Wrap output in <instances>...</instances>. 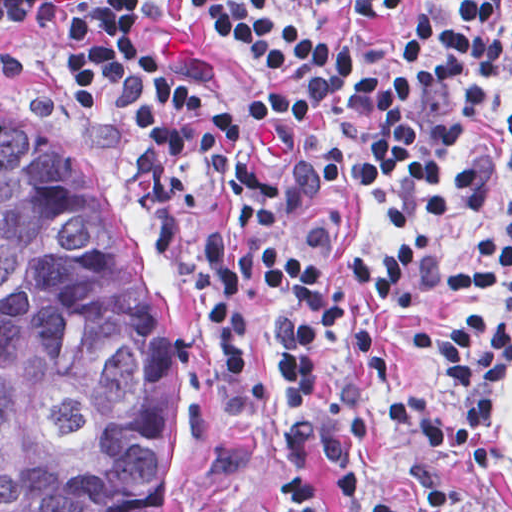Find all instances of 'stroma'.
Instances as JSON below:
<instances>
[{
	"mask_svg": "<svg viewBox=\"0 0 512 512\" xmlns=\"http://www.w3.org/2000/svg\"><path fill=\"white\" fill-rule=\"evenodd\" d=\"M0 1H498L512 23V0H0ZM66 36L56 24L0 21V120L18 128L64 132L84 141L112 211L133 253L169 306V487L154 512H254L282 479L313 482L339 512H378L403 494L418 512H512V357L490 407L491 459L483 467L444 463L443 453L394 430L372 399L370 430L339 460L330 456L329 401L346 387V344L336 328L308 400V450L295 459L285 427L287 385L273 350L266 297L249 314V367L267 405L248 422L238 391L222 376L171 265L160 207L146 184L133 144L105 102L60 69ZM512 113V57L491 92ZM512 213V170L477 208L424 226L395 224L368 197L314 200L277 232L297 257L327 280L357 317L376 353L402 385L440 391L446 367L416 351L419 333L439 329L466 309H491L496 292L448 286L405 308L350 277L354 259H385L425 238L438 261L469 257L477 240Z\"/></svg>",
	"mask_w": 512,
	"mask_h": 512,
	"instance_id": "35a3bbf8",
	"label": "stroma"
}]
</instances>
